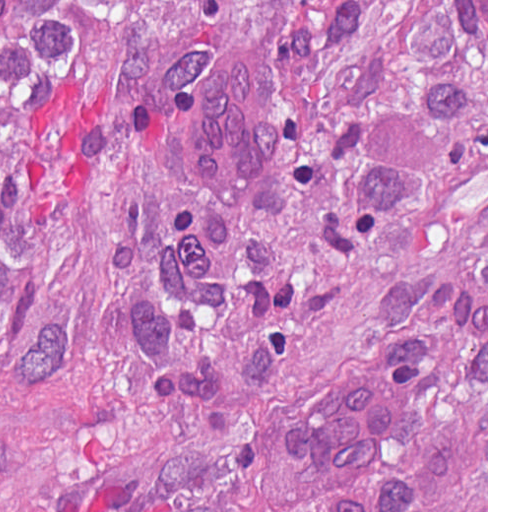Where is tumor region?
Masks as SVG:
<instances>
[{"mask_svg": "<svg viewBox=\"0 0 512 512\" xmlns=\"http://www.w3.org/2000/svg\"><path fill=\"white\" fill-rule=\"evenodd\" d=\"M0 512H487V0H0Z\"/></svg>", "mask_w": 512, "mask_h": 512, "instance_id": "obj_1", "label": "tumor region"}]
</instances>
